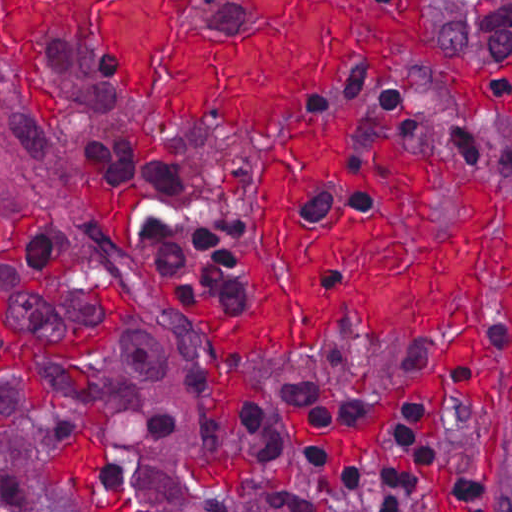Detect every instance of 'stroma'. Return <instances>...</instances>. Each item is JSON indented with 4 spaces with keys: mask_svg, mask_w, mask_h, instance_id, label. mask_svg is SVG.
Wrapping results in <instances>:
<instances>
[{
    "mask_svg": "<svg viewBox=\"0 0 512 512\" xmlns=\"http://www.w3.org/2000/svg\"><path fill=\"white\" fill-rule=\"evenodd\" d=\"M178 0L180 11L214 41ZM442 30V58L404 49L387 71L347 46L348 67L335 89L298 118L313 121L341 106L365 114L416 109L413 121L390 133L394 146L421 155L444 154L456 164L457 182L447 183L433 165L432 235L453 236L463 217L457 186L489 183L494 195L490 234L503 235L505 200L512 193V61L476 64L452 54ZM46 56L55 115L35 110L20 65L1 54L0 0V512H90L73 480L52 482L49 462L70 452L81 435L86 410L100 409L108 423L98 449L96 499L129 500V512H196L245 509L263 504L252 463L240 437L250 405L266 411L287 444L322 458L320 481L327 493L361 465L396 466L401 453L392 422L420 406L417 451L424 419L435 405L400 403L383 431L386 459L369 451L343 461L334 484L323 469L328 455L320 445L298 444L290 417L308 426H348L373 413V398L403 379L431 374L460 329L436 338L382 337L369 331L363 314L340 308L324 326L309 356L282 349L269 357L234 353L232 365L263 388L240 403L235 429L211 421L205 367L222 370L210 333L172 305L173 280L180 300L200 293L219 312L240 315L255 308L244 273V251L264 233L259 183L262 157L279 143L258 135L186 119L143 97L116 68L71 34L49 42ZM105 142L140 145L175 169L187 172L216 207L243 212L249 232L241 237L236 261L243 278L244 307L221 300L208 282L189 269L152 261L143 248L141 224L148 202L146 185L107 175L99 164ZM102 287L131 303V319L105 353L89 364L56 356L35 359V381L1 378V354L20 350L31 339L62 343L81 331H101ZM494 319L478 326L484 342L512 348L502 315L503 281L485 277ZM475 325L469 321L464 326ZM44 386V387H43ZM512 372L503 365L493 394L498 412L457 390L447 376L446 411L439 437L512 492V415L508 393ZM409 512H450L436 499L415 501Z\"/></svg>",
    "mask_w": 512,
    "mask_h": 512,
    "instance_id": "obj_1",
    "label": "stroma"
}]
</instances>
